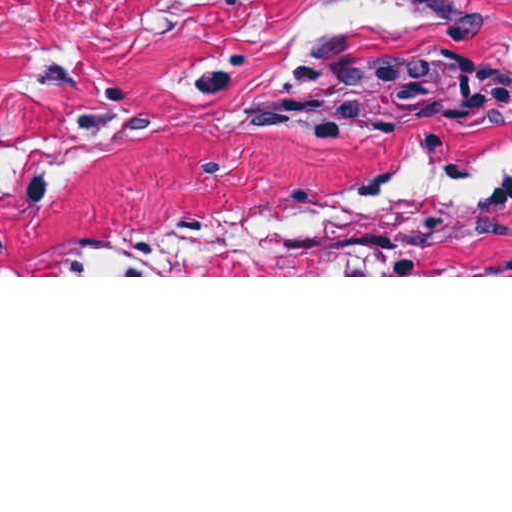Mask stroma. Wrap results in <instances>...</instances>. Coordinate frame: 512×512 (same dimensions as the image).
<instances>
[{"label": "stroma", "mask_w": 512, "mask_h": 512, "mask_svg": "<svg viewBox=\"0 0 512 512\" xmlns=\"http://www.w3.org/2000/svg\"><path fill=\"white\" fill-rule=\"evenodd\" d=\"M0 277H512V0H0Z\"/></svg>", "instance_id": "stroma-1"}]
</instances>
